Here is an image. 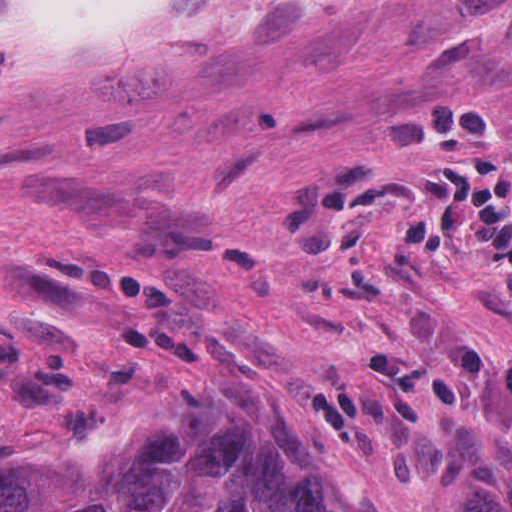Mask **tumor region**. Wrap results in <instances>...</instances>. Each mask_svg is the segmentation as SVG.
Wrapping results in <instances>:
<instances>
[{
    "mask_svg": "<svg viewBox=\"0 0 512 512\" xmlns=\"http://www.w3.org/2000/svg\"><path fill=\"white\" fill-rule=\"evenodd\" d=\"M1 512H367L353 471L268 385H180L122 444L9 449Z\"/></svg>",
    "mask_w": 512,
    "mask_h": 512,
    "instance_id": "e687c5a6",
    "label": "tumor region"
}]
</instances>
